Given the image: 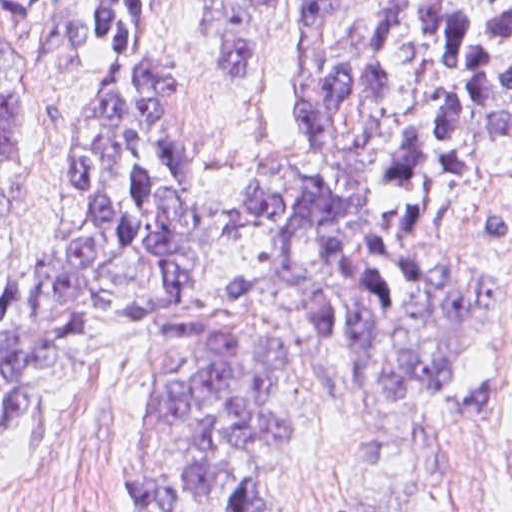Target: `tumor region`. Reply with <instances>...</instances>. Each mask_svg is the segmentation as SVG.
Returning <instances> with one entry per match:
<instances>
[{"mask_svg":"<svg viewBox=\"0 0 512 512\" xmlns=\"http://www.w3.org/2000/svg\"><path fill=\"white\" fill-rule=\"evenodd\" d=\"M151 1H0V458L52 385L135 350L185 378L132 432L128 512H266L312 429L278 336L234 318L248 287L195 281L201 203L183 117L189 72L120 80L86 124L48 245L15 257L35 180L32 48L110 59ZM267 1H223L207 53L223 77L252 59ZM288 75L302 150L240 194L238 247L267 266L315 347L322 424L357 421L362 512L386 456L423 482L405 427L454 387L462 344L501 295L427 245L470 192L478 154L512 167V1H304ZM512 264V210L483 213Z\"/></svg>","mask_w":512,"mask_h":512,"instance_id":"1","label":"tumor region"}]
</instances>
